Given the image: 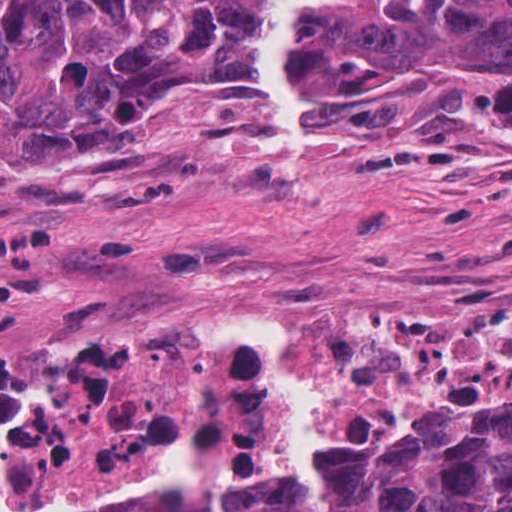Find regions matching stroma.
<instances>
[{
    "label": "stroma",
    "instance_id": "35a3bbf8",
    "mask_svg": "<svg viewBox=\"0 0 512 512\" xmlns=\"http://www.w3.org/2000/svg\"><path fill=\"white\" fill-rule=\"evenodd\" d=\"M323 134L272 148L256 97L169 119L124 164L0 145V358L57 355L166 320L249 313L411 317L512 310V110L457 76L389 98L313 97ZM512 384V357L407 392L361 447ZM226 416V391H225ZM175 433L146 432L109 477L0 512H130ZM225 484L292 460L285 435L223 434Z\"/></svg>",
    "mask_w": 512,
    "mask_h": 512
}]
</instances>
